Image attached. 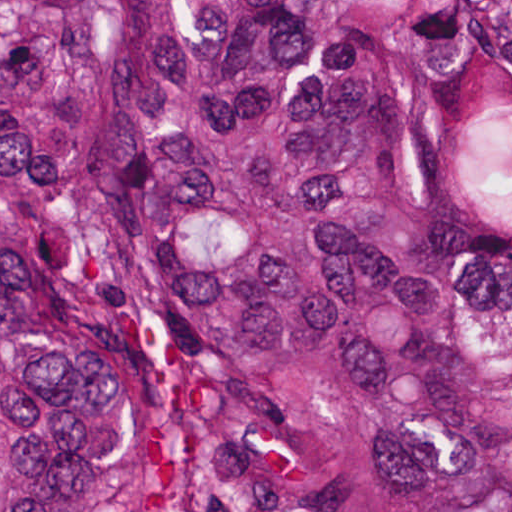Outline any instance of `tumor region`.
Here are the masks:
<instances>
[{"instance_id": "tumor-region-1", "label": "tumor region", "mask_w": 512, "mask_h": 512, "mask_svg": "<svg viewBox=\"0 0 512 512\" xmlns=\"http://www.w3.org/2000/svg\"><path fill=\"white\" fill-rule=\"evenodd\" d=\"M0 512H512V1H0Z\"/></svg>"}]
</instances>
